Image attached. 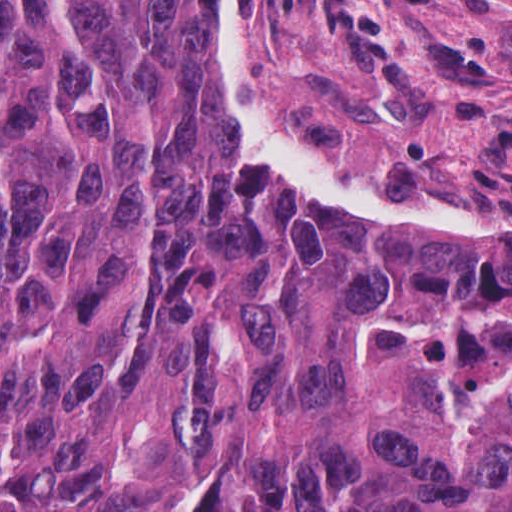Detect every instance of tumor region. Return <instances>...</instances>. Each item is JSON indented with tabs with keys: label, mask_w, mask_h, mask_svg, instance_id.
Returning a JSON list of instances; mask_svg holds the SVG:
<instances>
[{
	"label": "tumor region",
	"mask_w": 512,
	"mask_h": 512,
	"mask_svg": "<svg viewBox=\"0 0 512 512\" xmlns=\"http://www.w3.org/2000/svg\"><path fill=\"white\" fill-rule=\"evenodd\" d=\"M223 0H0V512H512V245L288 184Z\"/></svg>",
	"instance_id": "1"
}]
</instances>
